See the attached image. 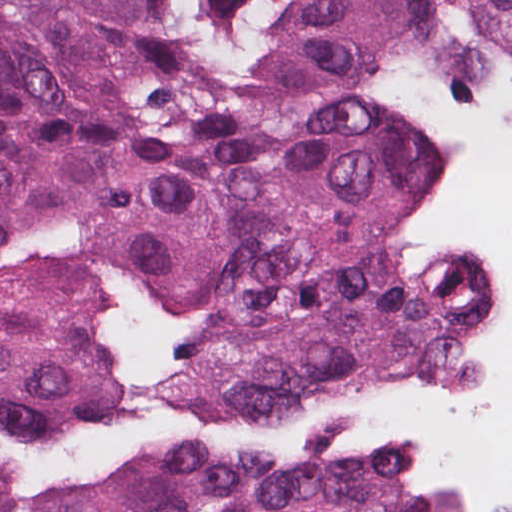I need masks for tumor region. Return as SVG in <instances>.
I'll use <instances>...</instances> for the list:
<instances>
[{
  "label": "tumor region",
  "instance_id": "obj_1",
  "mask_svg": "<svg viewBox=\"0 0 512 512\" xmlns=\"http://www.w3.org/2000/svg\"><path fill=\"white\" fill-rule=\"evenodd\" d=\"M462 8L300 0L364 68ZM497 309L434 148L229 74L202 0H0V512H423Z\"/></svg>",
  "mask_w": 512,
  "mask_h": 512
}]
</instances>
